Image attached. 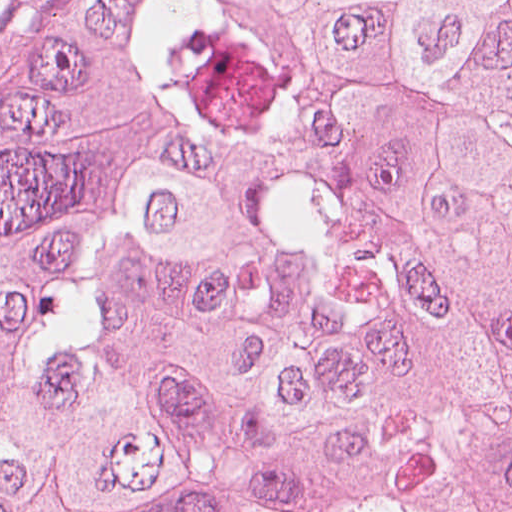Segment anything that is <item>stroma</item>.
<instances>
[{
    "mask_svg": "<svg viewBox=\"0 0 512 512\" xmlns=\"http://www.w3.org/2000/svg\"><path fill=\"white\" fill-rule=\"evenodd\" d=\"M77 0H0V122L47 32Z\"/></svg>",
    "mask_w": 512,
    "mask_h": 512,
    "instance_id": "1",
    "label": "stroma"
}]
</instances>
